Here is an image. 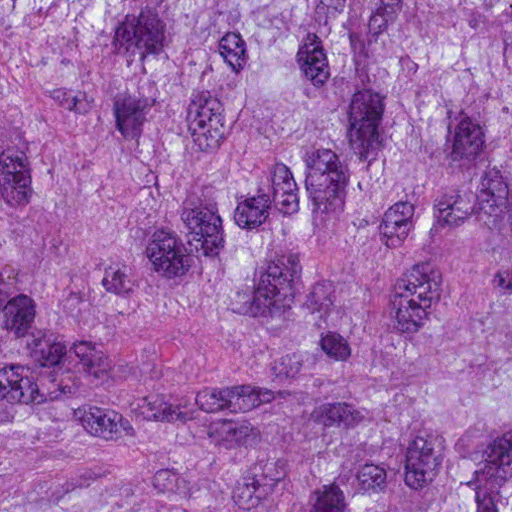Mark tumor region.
Masks as SVG:
<instances>
[{"label":"tumor region","instance_id":"obj_1","mask_svg":"<svg viewBox=\"0 0 512 512\" xmlns=\"http://www.w3.org/2000/svg\"><path fill=\"white\" fill-rule=\"evenodd\" d=\"M0 512H512V0H1Z\"/></svg>","mask_w":512,"mask_h":512}]
</instances>
